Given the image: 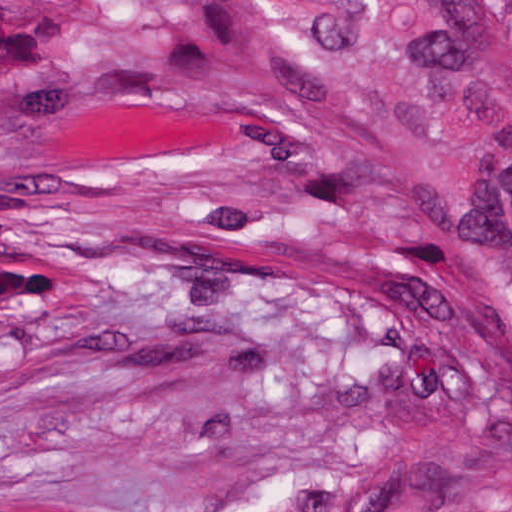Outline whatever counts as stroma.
<instances>
[{"label": "stroma", "mask_w": 512, "mask_h": 512, "mask_svg": "<svg viewBox=\"0 0 512 512\" xmlns=\"http://www.w3.org/2000/svg\"><path fill=\"white\" fill-rule=\"evenodd\" d=\"M427 232L203 0H0V512H385Z\"/></svg>", "instance_id": "stroma-1"}]
</instances>
